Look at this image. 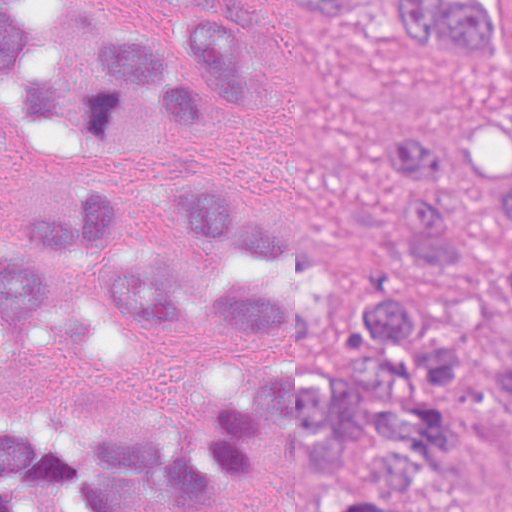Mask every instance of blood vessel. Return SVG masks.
Returning <instances> with one entry per match:
<instances>
[{
	"label": "blood vessel",
	"instance_id": "blood-vessel-1",
	"mask_svg": "<svg viewBox=\"0 0 512 512\" xmlns=\"http://www.w3.org/2000/svg\"><path fill=\"white\" fill-rule=\"evenodd\" d=\"M497 512H512V478L503 494Z\"/></svg>",
	"mask_w": 512,
	"mask_h": 512
}]
</instances>
